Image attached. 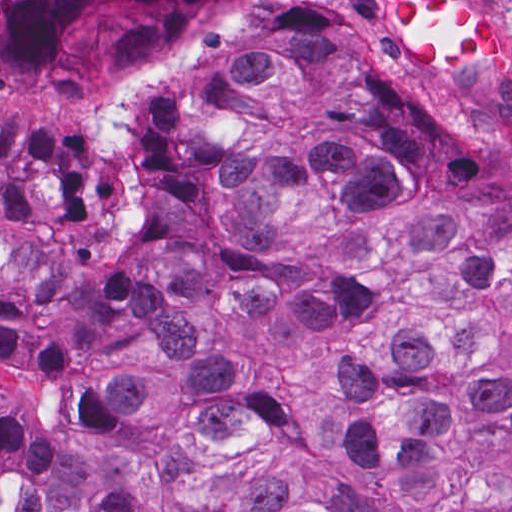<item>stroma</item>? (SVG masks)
Listing matches in <instances>:
<instances>
[{
  "label": "stroma",
  "instance_id": "1",
  "mask_svg": "<svg viewBox=\"0 0 512 512\" xmlns=\"http://www.w3.org/2000/svg\"><path fill=\"white\" fill-rule=\"evenodd\" d=\"M503 18L508 54L493 59L442 57L411 72L428 98L481 121L512 126V0H472ZM273 6L318 8L391 61L370 0H221L166 63L144 62L83 80L70 93L0 83V130L48 142L75 157L99 196L126 184L138 115L152 84L174 67L213 50L234 30ZM392 62V61H391ZM393 63V62H392Z\"/></svg>",
  "mask_w": 512,
  "mask_h": 512
}]
</instances>
